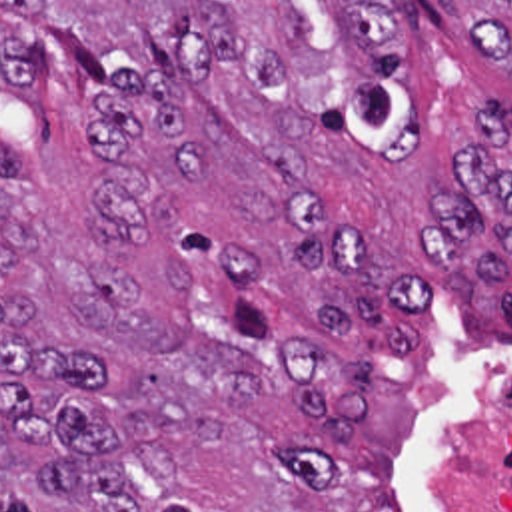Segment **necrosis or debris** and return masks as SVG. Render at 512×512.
<instances>
[{
  "instance_id": "obj_1",
  "label": "necrosis or debris",
  "mask_w": 512,
  "mask_h": 512,
  "mask_svg": "<svg viewBox=\"0 0 512 512\" xmlns=\"http://www.w3.org/2000/svg\"><path fill=\"white\" fill-rule=\"evenodd\" d=\"M453 495L457 512H512V371L461 413Z\"/></svg>"
}]
</instances>
